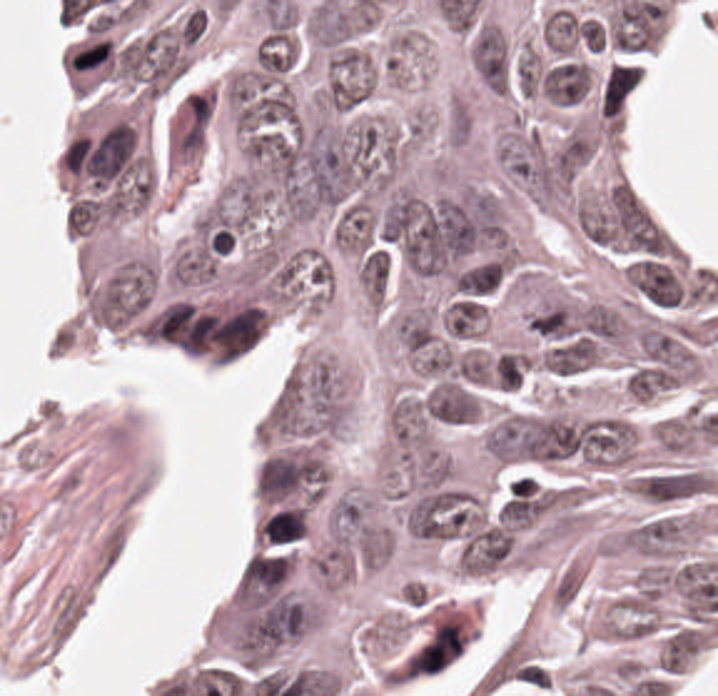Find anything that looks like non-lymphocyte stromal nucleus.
I'll return each mask as SVG.
<instances>
[{"label": "non-lymphocyte stromal nucleus", "mask_w": 718, "mask_h": 696, "mask_svg": "<svg viewBox=\"0 0 718 696\" xmlns=\"http://www.w3.org/2000/svg\"><path fill=\"white\" fill-rule=\"evenodd\" d=\"M92 585L85 575H72L54 585L40 620L42 643L56 655L85 616Z\"/></svg>", "instance_id": "non-lymphocyte-stromal-nucleus-1"}]
</instances>
